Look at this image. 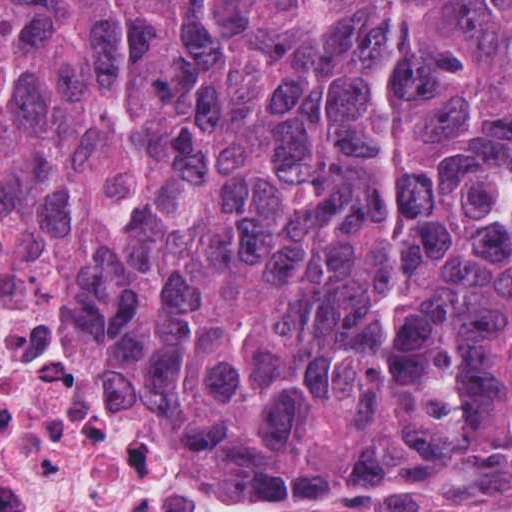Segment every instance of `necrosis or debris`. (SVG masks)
Returning <instances> with one entry per match:
<instances>
[{"label": "necrosis or debris", "instance_id": "4bbe7bcc", "mask_svg": "<svg viewBox=\"0 0 512 512\" xmlns=\"http://www.w3.org/2000/svg\"><path fill=\"white\" fill-rule=\"evenodd\" d=\"M0 512H226L147 379L1 244Z\"/></svg>", "mask_w": 512, "mask_h": 512}]
</instances>
